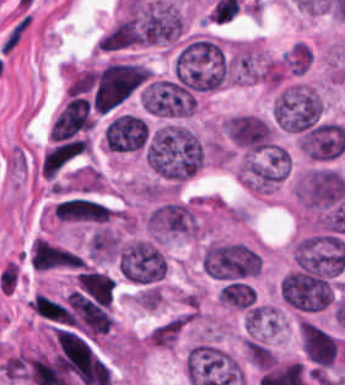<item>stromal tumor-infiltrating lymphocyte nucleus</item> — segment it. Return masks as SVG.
Returning a JSON list of instances; mask_svg holds the SVG:
<instances>
[{"label":"stromal tumor-infiltrating lymphocyte nucleus","mask_w":345,"mask_h":385,"mask_svg":"<svg viewBox=\"0 0 345 385\" xmlns=\"http://www.w3.org/2000/svg\"><path fill=\"white\" fill-rule=\"evenodd\" d=\"M259 265H260V261H259V257L257 254V257H256V273H257V275H258V271H259Z\"/></svg>","instance_id":"1"}]
</instances>
